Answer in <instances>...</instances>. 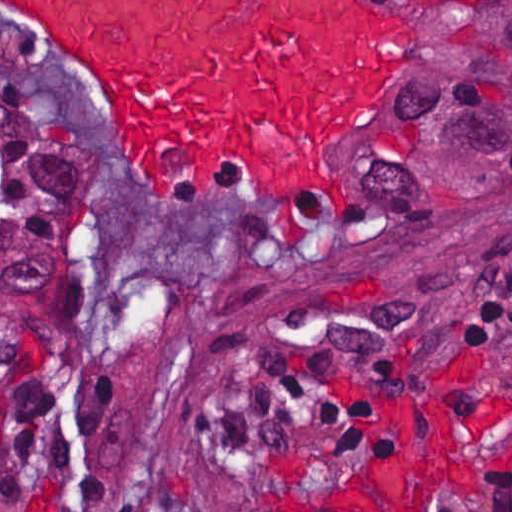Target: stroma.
<instances>
[{
  "label": "stroma",
  "instance_id": "obj_1",
  "mask_svg": "<svg viewBox=\"0 0 512 512\" xmlns=\"http://www.w3.org/2000/svg\"><path fill=\"white\" fill-rule=\"evenodd\" d=\"M383 1L398 23L395 59L347 133L337 225L316 237L284 235L261 204L208 200L190 211L137 181L64 58L0 13L1 92L95 150L80 220L85 265L55 325H0V403L80 377L120 395L102 500L41 477L0 486V512H241L380 481L405 469L419 411L437 395L458 460L432 512L473 511L488 466L512 452V328L463 335L459 316L512 260V194L413 249L380 255L373 245L369 140L430 30L419 0ZM370 183L381 230L382 136ZM318 336L390 357L402 398L391 454L361 457L267 406L262 382Z\"/></svg>",
  "mask_w": 512,
  "mask_h": 512
}]
</instances>
